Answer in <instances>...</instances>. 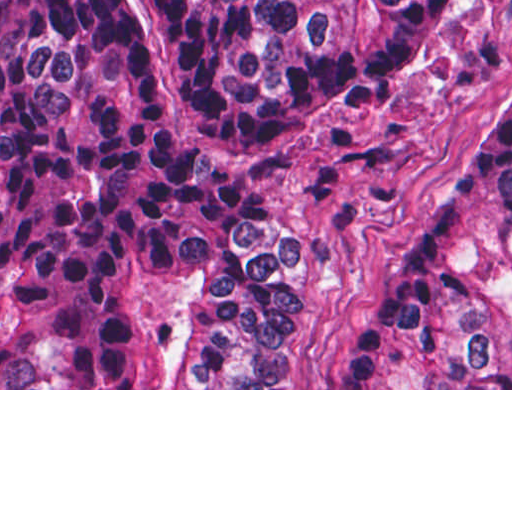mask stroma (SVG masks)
<instances>
[{
  "instance_id": "obj_1",
  "label": "stroma",
  "mask_w": 512,
  "mask_h": 512,
  "mask_svg": "<svg viewBox=\"0 0 512 512\" xmlns=\"http://www.w3.org/2000/svg\"><path fill=\"white\" fill-rule=\"evenodd\" d=\"M113 4L117 17H135V0ZM511 78L512 0H474L458 35L396 92L227 168L218 187L236 205L299 229L288 377L274 388H1L0 0V390H512L344 386L367 314L436 218Z\"/></svg>"
}]
</instances>
